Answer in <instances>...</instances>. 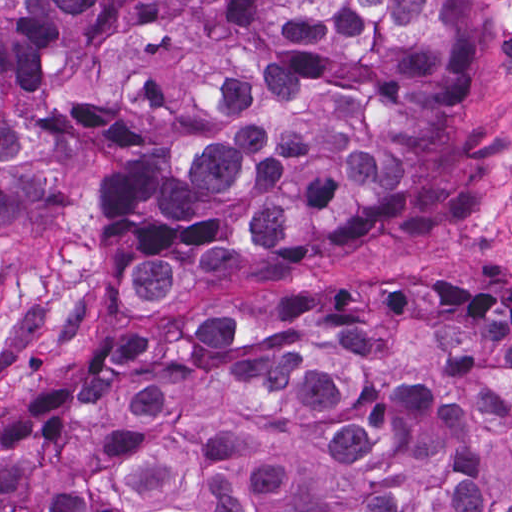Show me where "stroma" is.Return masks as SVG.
Listing matches in <instances>:
<instances>
[{
    "instance_id": "1",
    "label": "stroma",
    "mask_w": 512,
    "mask_h": 512,
    "mask_svg": "<svg viewBox=\"0 0 512 512\" xmlns=\"http://www.w3.org/2000/svg\"><path fill=\"white\" fill-rule=\"evenodd\" d=\"M476 62L461 139L476 202L423 234H337L299 267L248 261L219 278L186 272L163 296L125 295V245L97 234L91 200L40 206L0 225V427L49 378L118 356L184 310H255L292 276H345L444 293L512 290V0H472Z\"/></svg>"
}]
</instances>
